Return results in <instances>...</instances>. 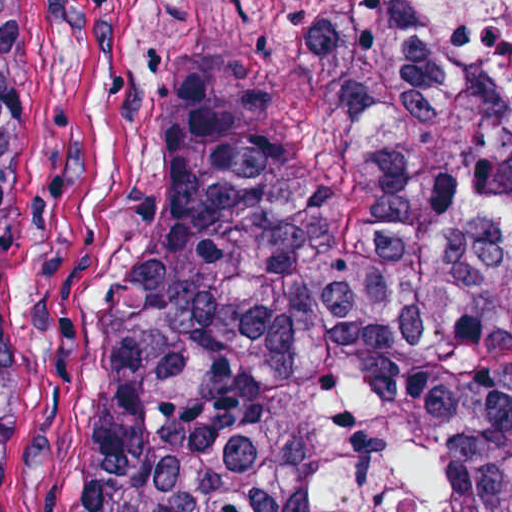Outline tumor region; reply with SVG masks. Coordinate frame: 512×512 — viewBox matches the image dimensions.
Here are the masks:
<instances>
[{
  "mask_svg": "<svg viewBox=\"0 0 512 512\" xmlns=\"http://www.w3.org/2000/svg\"><path fill=\"white\" fill-rule=\"evenodd\" d=\"M322 78L267 113L177 63L89 317L71 512H323L317 389L432 423L439 512H512V98H460L384 0H287ZM27 239L0 52V512Z\"/></svg>",
  "mask_w": 512,
  "mask_h": 512,
  "instance_id": "obj_1",
  "label": "tumor region"
}]
</instances>
